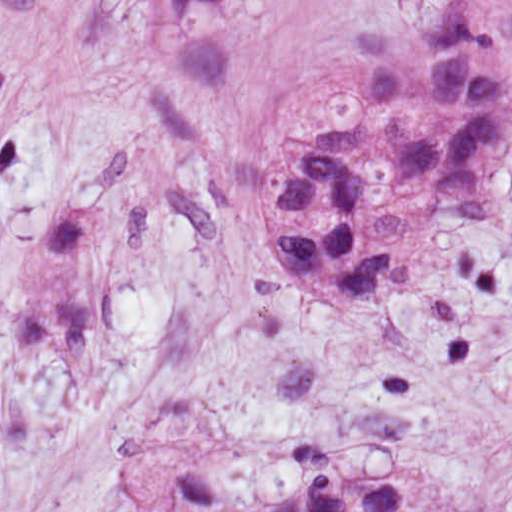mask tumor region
<instances>
[{"label":"tumor region","mask_w":512,"mask_h":512,"mask_svg":"<svg viewBox=\"0 0 512 512\" xmlns=\"http://www.w3.org/2000/svg\"><path fill=\"white\" fill-rule=\"evenodd\" d=\"M361 107L343 132L292 141L260 215L279 290L322 308L368 305L430 231L482 220L504 132L502 0H456L421 34L355 42ZM405 470L320 476L264 512H356Z\"/></svg>","instance_id":"e687c5a6"}]
</instances>
